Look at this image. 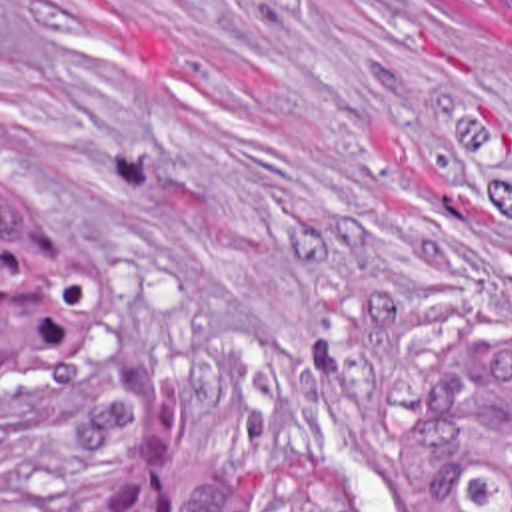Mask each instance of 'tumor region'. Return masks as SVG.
<instances>
[{"label":"tumor region","mask_w":512,"mask_h":512,"mask_svg":"<svg viewBox=\"0 0 512 512\" xmlns=\"http://www.w3.org/2000/svg\"><path fill=\"white\" fill-rule=\"evenodd\" d=\"M512 18V0H498ZM102 327V277L82 245L0 199V387L62 369ZM396 449L434 512H512V335L470 339L434 361L398 407ZM0 512H52L34 429L0 439ZM90 512H354L304 461H254L202 483L180 505L158 495L124 443Z\"/></svg>","instance_id":"tumor-region-1"}]
</instances>
